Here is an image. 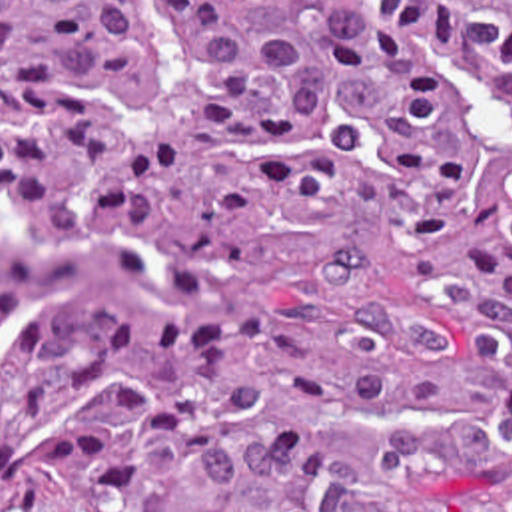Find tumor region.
I'll return each mask as SVG.
<instances>
[{
	"mask_svg": "<svg viewBox=\"0 0 512 512\" xmlns=\"http://www.w3.org/2000/svg\"><path fill=\"white\" fill-rule=\"evenodd\" d=\"M0 512H512V0H0Z\"/></svg>",
	"mask_w": 512,
	"mask_h": 512,
	"instance_id": "tumor-region-1",
	"label": "tumor region"
}]
</instances>
